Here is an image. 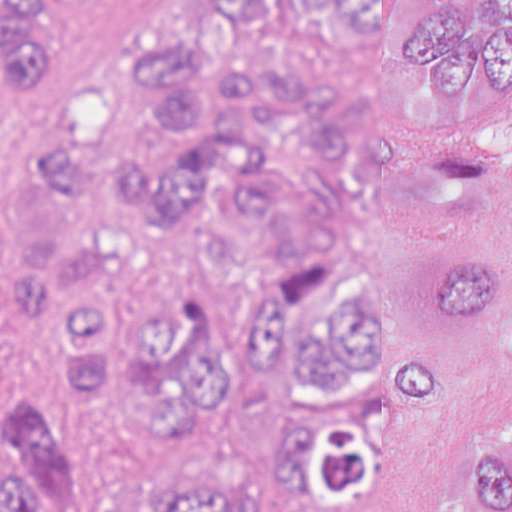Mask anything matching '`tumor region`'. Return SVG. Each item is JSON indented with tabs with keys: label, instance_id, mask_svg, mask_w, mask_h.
<instances>
[{
	"label": "tumor region",
	"instance_id": "tumor-region-1",
	"mask_svg": "<svg viewBox=\"0 0 512 512\" xmlns=\"http://www.w3.org/2000/svg\"><path fill=\"white\" fill-rule=\"evenodd\" d=\"M109 72L0 208V512H381L456 336L512 338V0H203ZM438 512H512V444Z\"/></svg>",
	"mask_w": 512,
	"mask_h": 512
}]
</instances>
